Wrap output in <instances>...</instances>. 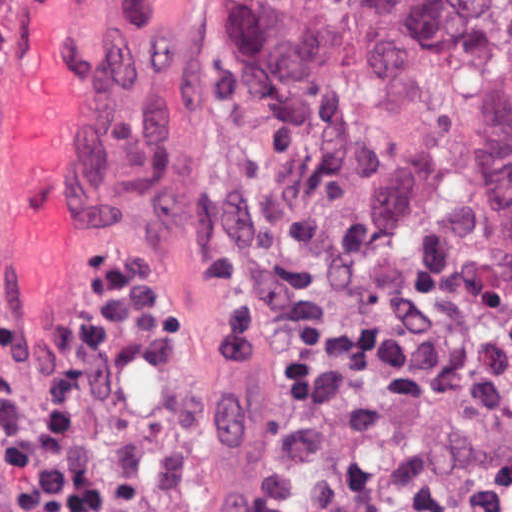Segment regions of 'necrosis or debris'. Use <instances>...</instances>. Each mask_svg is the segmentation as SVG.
I'll return each instance as SVG.
<instances>
[{"label": "necrosis or debris", "mask_w": 512, "mask_h": 512, "mask_svg": "<svg viewBox=\"0 0 512 512\" xmlns=\"http://www.w3.org/2000/svg\"><path fill=\"white\" fill-rule=\"evenodd\" d=\"M214 281L239 357L289 389L234 431L146 312L89 439L98 512H512V313L250 266Z\"/></svg>", "instance_id": "4bbe7bcc"}]
</instances>
